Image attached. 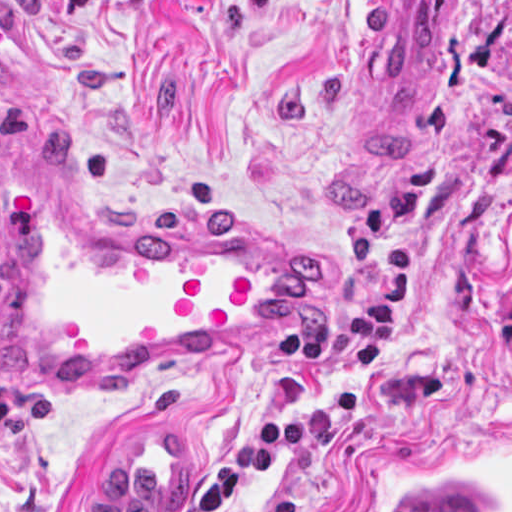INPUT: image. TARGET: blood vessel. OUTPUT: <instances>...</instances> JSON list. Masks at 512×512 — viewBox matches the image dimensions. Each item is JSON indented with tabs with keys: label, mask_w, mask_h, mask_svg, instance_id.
<instances>
[{
	"label": "blood vessel",
	"mask_w": 512,
	"mask_h": 512,
	"mask_svg": "<svg viewBox=\"0 0 512 512\" xmlns=\"http://www.w3.org/2000/svg\"><path fill=\"white\" fill-rule=\"evenodd\" d=\"M458 0H374L365 65L394 103L420 102ZM212 221H154L80 191L63 143L0 132V381L70 397L168 365L285 340L341 287L331 264ZM188 438L129 434L87 476L81 512H174Z\"/></svg>",
	"instance_id": "1"
}]
</instances>
